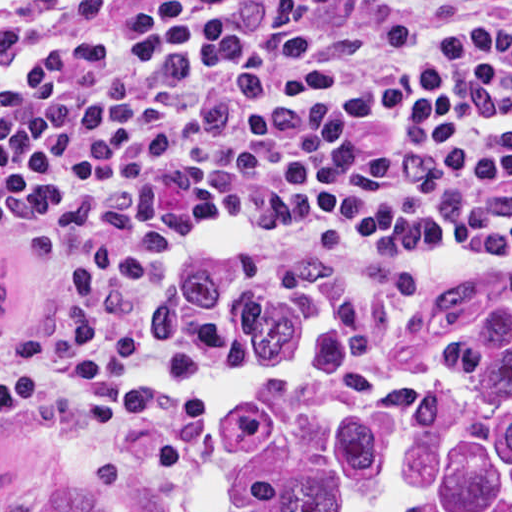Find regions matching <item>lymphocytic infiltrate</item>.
Wrapping results in <instances>:
<instances>
[{
  "label": "lymphocytic infiltrate",
  "instance_id": "f902f5d3",
  "mask_svg": "<svg viewBox=\"0 0 512 512\" xmlns=\"http://www.w3.org/2000/svg\"><path fill=\"white\" fill-rule=\"evenodd\" d=\"M512 229V0H67L0 54V413L255 251Z\"/></svg>",
  "mask_w": 512,
  "mask_h": 512
}]
</instances>
